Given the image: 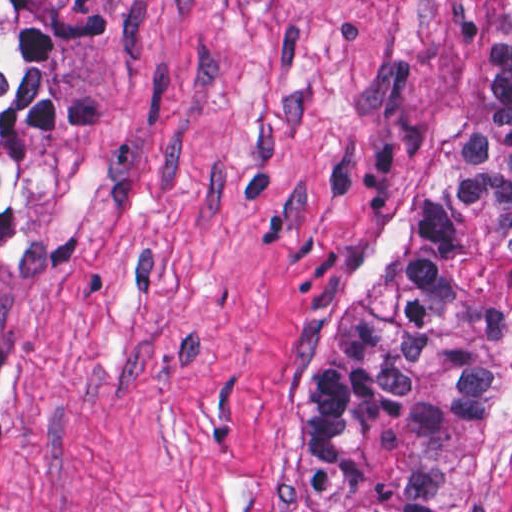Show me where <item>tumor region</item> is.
<instances>
[{
    "instance_id": "1",
    "label": "tumor region",
    "mask_w": 512,
    "mask_h": 512,
    "mask_svg": "<svg viewBox=\"0 0 512 512\" xmlns=\"http://www.w3.org/2000/svg\"><path fill=\"white\" fill-rule=\"evenodd\" d=\"M107 117L59 79L52 1L0 0V228L23 143ZM288 397L296 512H479L512 423V0L449 162L300 327Z\"/></svg>"
}]
</instances>
